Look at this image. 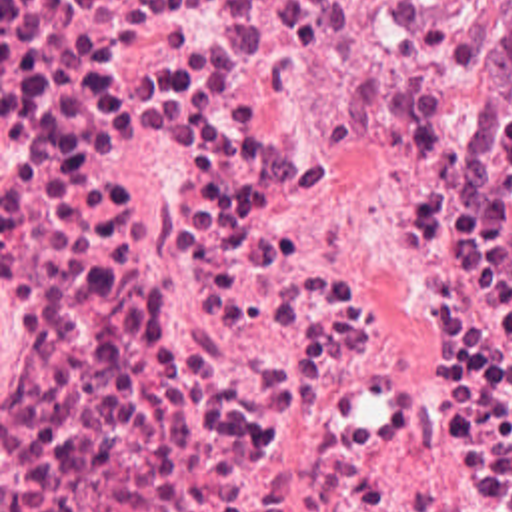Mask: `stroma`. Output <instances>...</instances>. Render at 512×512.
<instances>
[{
  "mask_svg": "<svg viewBox=\"0 0 512 512\" xmlns=\"http://www.w3.org/2000/svg\"><path fill=\"white\" fill-rule=\"evenodd\" d=\"M448 59L456 75L500 99H510L494 75L492 0H470V7L452 37Z\"/></svg>",
  "mask_w": 512,
  "mask_h": 512,
  "instance_id": "1",
  "label": "stroma"
}]
</instances>
